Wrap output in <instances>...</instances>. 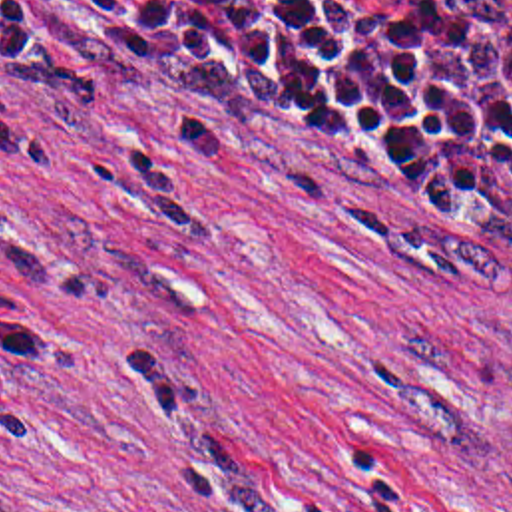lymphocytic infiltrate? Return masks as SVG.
I'll use <instances>...</instances> for the list:
<instances>
[{"instance_id":"1","label":"lymphocytic infiltrate","mask_w":512,"mask_h":512,"mask_svg":"<svg viewBox=\"0 0 512 512\" xmlns=\"http://www.w3.org/2000/svg\"><path fill=\"white\" fill-rule=\"evenodd\" d=\"M0 81L258 122L512 254V0H0Z\"/></svg>"}]
</instances>
